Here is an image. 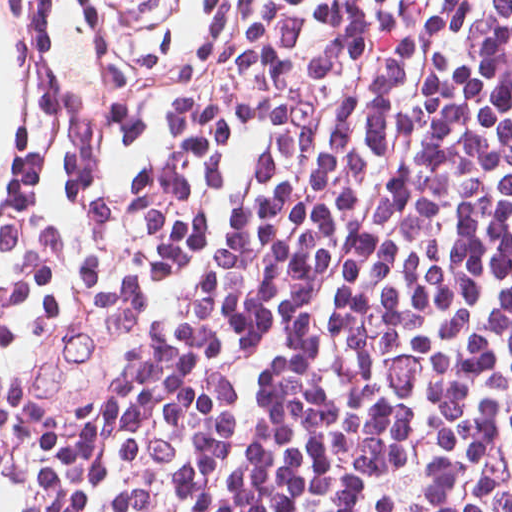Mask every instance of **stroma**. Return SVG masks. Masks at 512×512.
<instances>
[{"mask_svg":"<svg viewBox=\"0 0 512 512\" xmlns=\"http://www.w3.org/2000/svg\"><path fill=\"white\" fill-rule=\"evenodd\" d=\"M232 3L168 0L111 272L127 248L156 237L166 219Z\"/></svg>","mask_w":512,"mask_h":512,"instance_id":"1","label":"stroma"}]
</instances>
